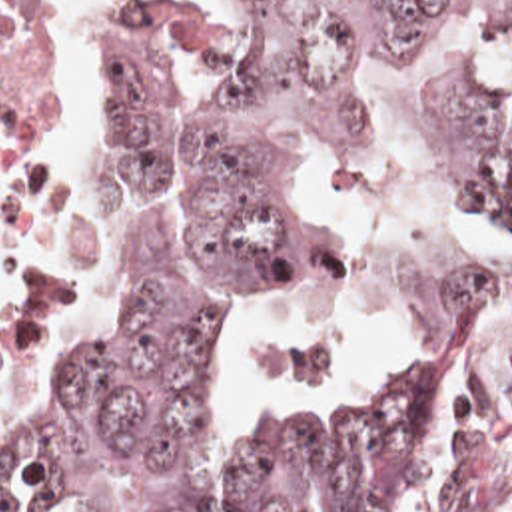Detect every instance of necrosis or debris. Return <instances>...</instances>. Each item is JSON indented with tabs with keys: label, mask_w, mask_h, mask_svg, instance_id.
Wrapping results in <instances>:
<instances>
[{
	"label": "necrosis or debris",
	"mask_w": 512,
	"mask_h": 512,
	"mask_svg": "<svg viewBox=\"0 0 512 512\" xmlns=\"http://www.w3.org/2000/svg\"><path fill=\"white\" fill-rule=\"evenodd\" d=\"M49 206V0H0V354Z\"/></svg>",
	"instance_id": "4bbe7bcc"
}]
</instances>
